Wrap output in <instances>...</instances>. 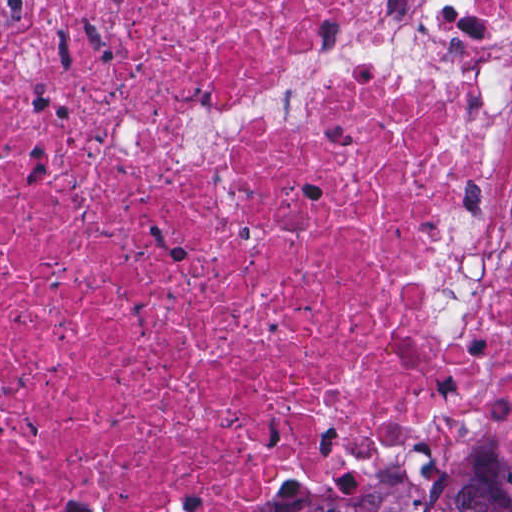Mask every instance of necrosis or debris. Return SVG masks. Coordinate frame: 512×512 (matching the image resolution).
<instances>
[{"instance_id":"4bbe7bcc","label":"necrosis or debris","mask_w":512,"mask_h":512,"mask_svg":"<svg viewBox=\"0 0 512 512\" xmlns=\"http://www.w3.org/2000/svg\"><path fill=\"white\" fill-rule=\"evenodd\" d=\"M411 1H0V512H250L462 366L416 275L489 86L315 74L182 162L178 122Z\"/></svg>"}]
</instances>
